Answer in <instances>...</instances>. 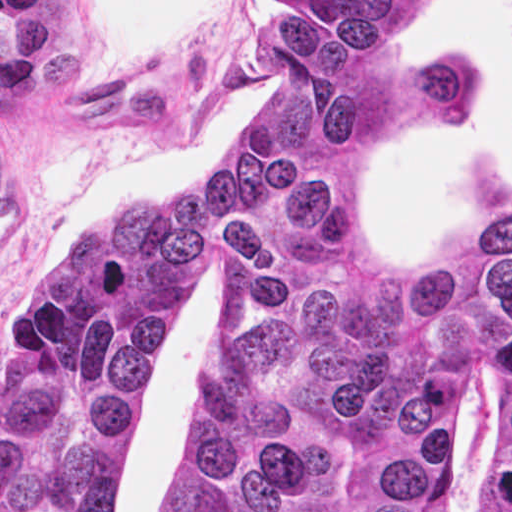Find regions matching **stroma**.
Returning a JSON list of instances; mask_svg holds the SVG:
<instances>
[{"instance_id":"1","label":"stroma","mask_w":512,"mask_h":512,"mask_svg":"<svg viewBox=\"0 0 512 512\" xmlns=\"http://www.w3.org/2000/svg\"><path fill=\"white\" fill-rule=\"evenodd\" d=\"M389 40L426 58L473 54L489 76L483 108L394 134L359 195L385 251L434 266L512 202V0H417ZM270 63L271 0H242L233 36L201 67L107 96L86 87L77 0H0V362L50 256L100 213L147 203L227 157L262 104ZM229 317L200 248L169 361L129 444L121 512H167L183 421ZM497 405L498 372H468L452 512H484Z\"/></svg>"}]
</instances>
